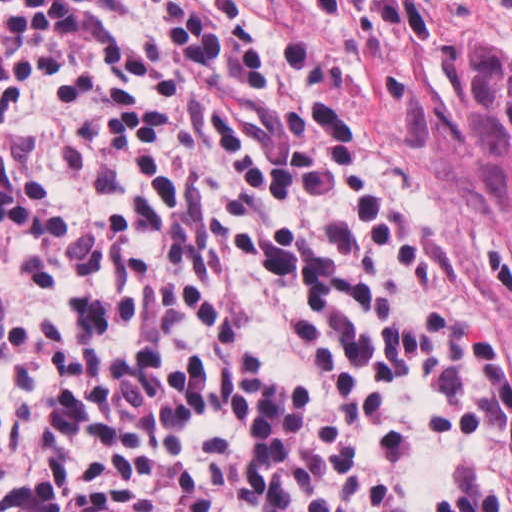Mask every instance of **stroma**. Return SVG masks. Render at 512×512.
I'll list each match as a JSON object with an SVG mask.
<instances>
[{"mask_svg":"<svg viewBox=\"0 0 512 512\" xmlns=\"http://www.w3.org/2000/svg\"><path fill=\"white\" fill-rule=\"evenodd\" d=\"M363 130L454 276L512 332V229L471 195L455 31L512 59V0H310Z\"/></svg>","mask_w":512,"mask_h":512,"instance_id":"1","label":"stroma"}]
</instances>
